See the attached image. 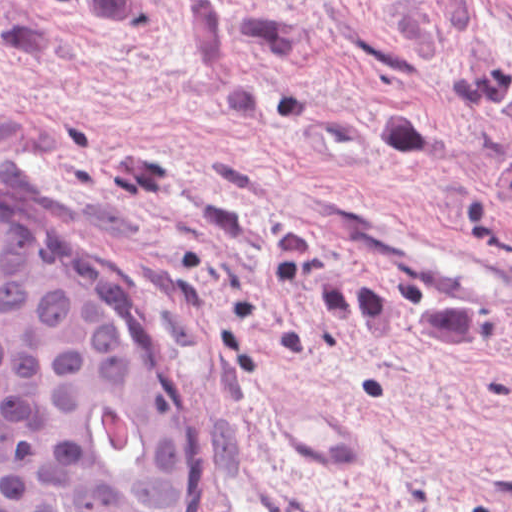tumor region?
Listing matches in <instances>:
<instances>
[{
    "instance_id": "1",
    "label": "tumor region",
    "mask_w": 512,
    "mask_h": 512,
    "mask_svg": "<svg viewBox=\"0 0 512 512\" xmlns=\"http://www.w3.org/2000/svg\"><path fill=\"white\" fill-rule=\"evenodd\" d=\"M365 136L368 149L379 162L400 168L420 163L423 120L405 104L377 107L367 118Z\"/></svg>"
}]
</instances>
